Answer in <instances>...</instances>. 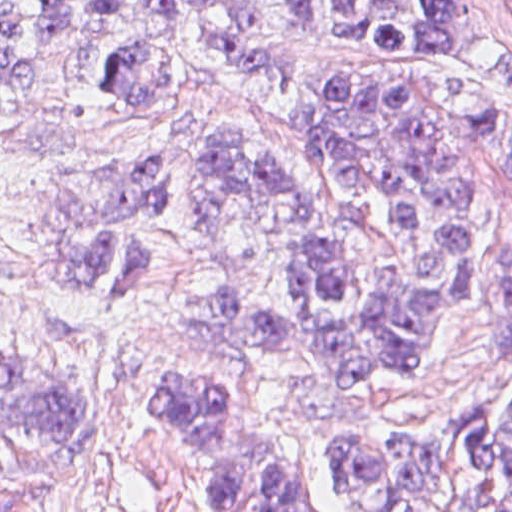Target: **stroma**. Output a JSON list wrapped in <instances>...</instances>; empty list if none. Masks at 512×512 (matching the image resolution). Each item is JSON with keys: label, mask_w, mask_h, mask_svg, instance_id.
I'll list each match as a JSON object with an SVG mask.
<instances>
[{"label": "stroma", "mask_w": 512, "mask_h": 512, "mask_svg": "<svg viewBox=\"0 0 512 512\" xmlns=\"http://www.w3.org/2000/svg\"><path fill=\"white\" fill-rule=\"evenodd\" d=\"M319 1L320 24L328 27L334 0ZM169 33L177 73L155 98H127L106 85L99 71L104 39L75 30L43 58L30 89L0 109V353L71 371L108 403L95 395L89 402L79 451L0 415V512H213L157 391V370L172 363H213L246 378L311 496L324 512H343L320 484L321 424L358 421L441 440L474 408L491 402L500 414L512 398V349H500L512 168L480 138L431 57L321 42L285 22L297 65L277 77L215 57L185 11L177 10ZM455 63L512 118V16L501 0H466ZM340 70L386 78L443 117L469 200L464 303L445 311L425 340L429 363L382 377L184 356L177 309L189 290L206 294L234 279L284 306L296 302V284L257 206H241L222 230L198 220L209 143L220 135L268 152L316 196L352 254L365 302L384 303L399 278L422 272L419 241L384 198L334 177L296 130L305 98L323 75ZM143 159L171 165L154 198V221L122 234L150 267L90 295L55 289L37 265V217L60 175ZM437 512L473 511L452 493Z\"/></svg>", "instance_id": "obj_1"}]
</instances>
